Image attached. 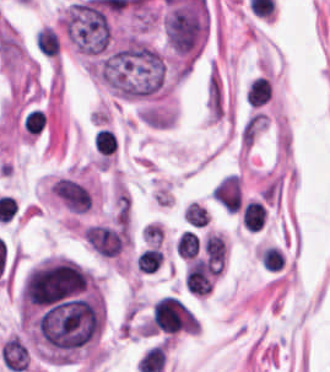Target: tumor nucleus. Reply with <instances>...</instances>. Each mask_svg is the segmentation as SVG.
<instances>
[{
  "instance_id": "tumor-nucleus-1",
  "label": "tumor nucleus",
  "mask_w": 330,
  "mask_h": 372,
  "mask_svg": "<svg viewBox=\"0 0 330 372\" xmlns=\"http://www.w3.org/2000/svg\"><path fill=\"white\" fill-rule=\"evenodd\" d=\"M68 39L80 51H102L109 41L108 19L95 0L77 1L63 17Z\"/></svg>"
}]
</instances>
